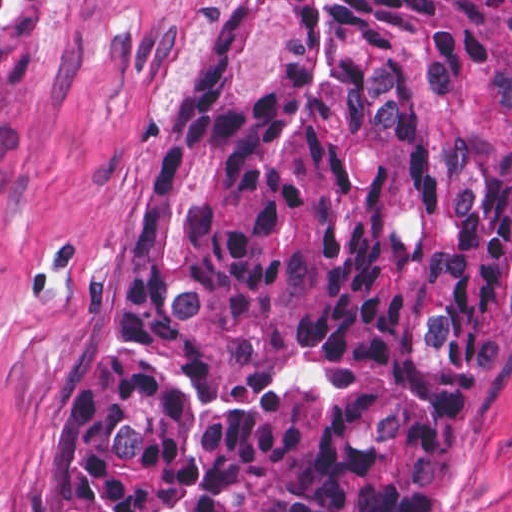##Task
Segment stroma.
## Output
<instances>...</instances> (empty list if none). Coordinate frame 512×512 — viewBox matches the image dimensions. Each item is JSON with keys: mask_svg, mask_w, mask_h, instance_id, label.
<instances>
[{"mask_svg": "<svg viewBox=\"0 0 512 512\" xmlns=\"http://www.w3.org/2000/svg\"><path fill=\"white\" fill-rule=\"evenodd\" d=\"M50 11L42 50L0 109V512H74L59 443L115 350L186 100L254 1L0 0ZM426 512H512V335Z\"/></svg>", "mask_w": 512, "mask_h": 512, "instance_id": "35a3bbf8", "label": "stroma"}]
</instances>
